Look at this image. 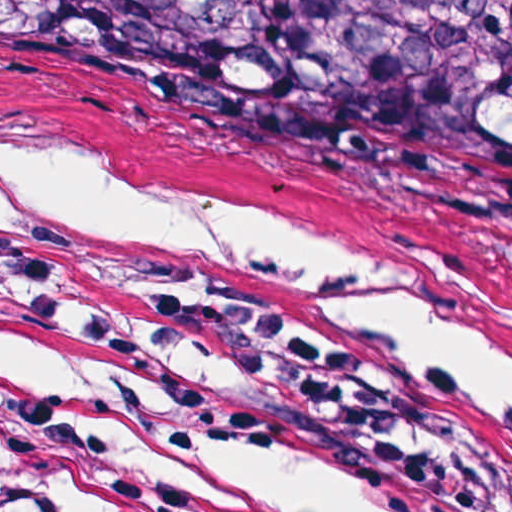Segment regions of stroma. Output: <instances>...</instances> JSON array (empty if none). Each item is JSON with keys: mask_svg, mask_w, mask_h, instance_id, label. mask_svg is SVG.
<instances>
[{"mask_svg": "<svg viewBox=\"0 0 512 512\" xmlns=\"http://www.w3.org/2000/svg\"><path fill=\"white\" fill-rule=\"evenodd\" d=\"M0 134L91 173L288 218L443 287L512 333V196L0 94ZM148 352L239 414L411 476L447 512H512V413L234 283L125 277ZM96 512L86 492L13 483Z\"/></svg>", "mask_w": 512, "mask_h": 512, "instance_id": "35a3bbf8", "label": "stroma"}]
</instances>
